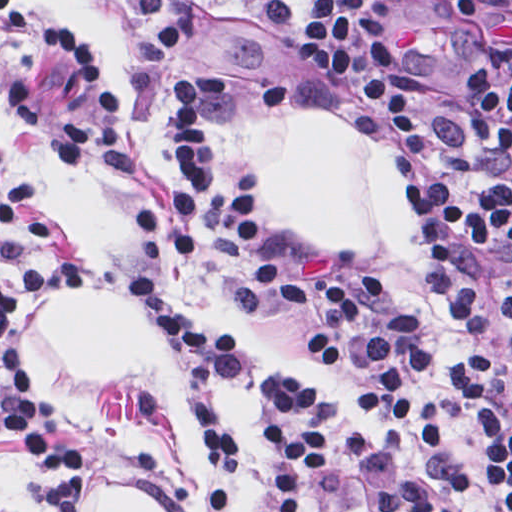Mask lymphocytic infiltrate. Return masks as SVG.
Here are the masks:
<instances>
[{"label": "lymphocytic infiltrate", "instance_id": "1", "mask_svg": "<svg viewBox=\"0 0 512 512\" xmlns=\"http://www.w3.org/2000/svg\"><path fill=\"white\" fill-rule=\"evenodd\" d=\"M153 30L196 4L302 68L360 86L400 148L391 186L411 219L459 328V358L429 397L428 343L414 315L372 316L390 289L372 271H314L268 230L226 162L218 92L204 64H184L168 87V150L157 196L130 210L162 255L137 267L127 294L174 341L195 373L240 370L233 323L184 281L183 253L214 223L240 252L265 310L308 324L303 364L357 409L312 412L304 380L286 374L262 391L271 512H319L328 464L355 458L378 437L447 448L456 420L476 441L492 512H512V378L508 397L474 276L512 271V0H116ZM0 70L34 88L93 94L89 72L58 41L0 3ZM55 227L30 181L0 208V264L22 274L0 286V437L21 440L29 497L40 512H82L95 484L92 450L65 442L28 372L15 323L25 306L94 285L80 263L43 256ZM212 512L237 498L240 443L197 394ZM374 512H458L428 478L396 471L372 485Z\"/></svg>", "mask_w": 512, "mask_h": 512}]
</instances>
